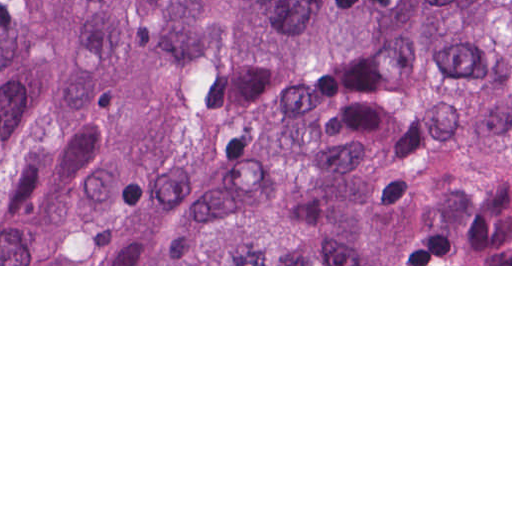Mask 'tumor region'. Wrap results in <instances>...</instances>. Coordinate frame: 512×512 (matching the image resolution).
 <instances>
[{
  "label": "tumor region",
  "mask_w": 512,
  "mask_h": 512,
  "mask_svg": "<svg viewBox=\"0 0 512 512\" xmlns=\"http://www.w3.org/2000/svg\"><path fill=\"white\" fill-rule=\"evenodd\" d=\"M0 264H512V0H0Z\"/></svg>",
  "instance_id": "1"
}]
</instances>
